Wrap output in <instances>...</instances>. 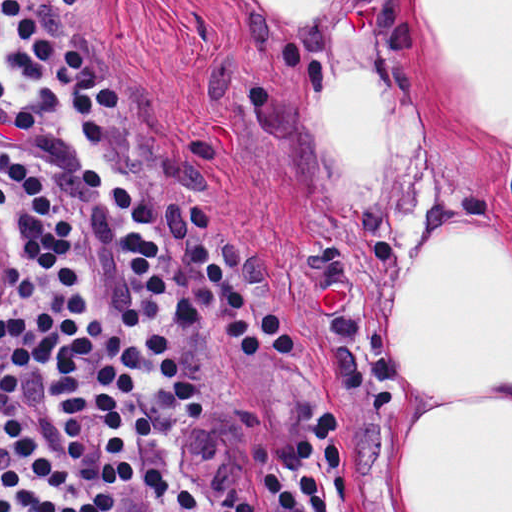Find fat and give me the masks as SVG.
<instances>
[{
	"mask_svg": "<svg viewBox=\"0 0 512 512\" xmlns=\"http://www.w3.org/2000/svg\"><path fill=\"white\" fill-rule=\"evenodd\" d=\"M260 31L304 74L308 146L361 235L413 219L422 169L401 76L421 41L452 101L512 143V0H250ZM396 391L408 512H512V254L463 218L400 286Z\"/></svg>",
	"mask_w": 512,
	"mask_h": 512,
	"instance_id": "1",
	"label": "fat"
}]
</instances>
